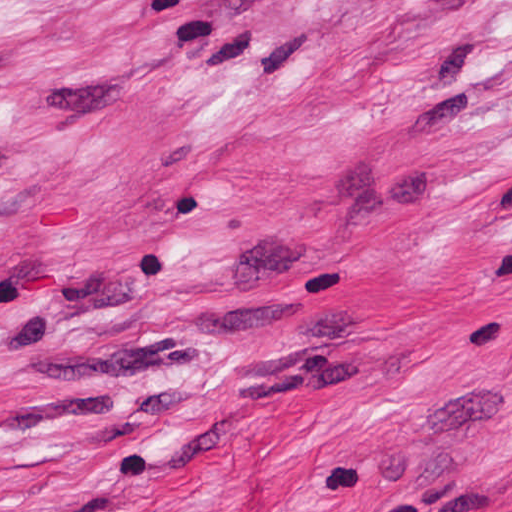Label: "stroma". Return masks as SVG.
I'll return each instance as SVG.
<instances>
[{
  "instance_id": "1",
  "label": "stroma",
  "mask_w": 512,
  "mask_h": 512,
  "mask_svg": "<svg viewBox=\"0 0 512 512\" xmlns=\"http://www.w3.org/2000/svg\"><path fill=\"white\" fill-rule=\"evenodd\" d=\"M0 512H512V0H0Z\"/></svg>"
}]
</instances>
